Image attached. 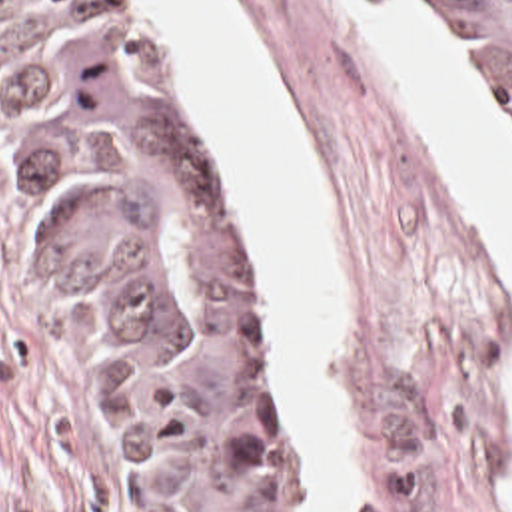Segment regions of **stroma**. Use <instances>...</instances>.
I'll list each match as a JSON object with an SVG mask.
<instances>
[{
	"instance_id": "obj_1",
	"label": "stroma",
	"mask_w": 512,
	"mask_h": 512,
	"mask_svg": "<svg viewBox=\"0 0 512 512\" xmlns=\"http://www.w3.org/2000/svg\"><path fill=\"white\" fill-rule=\"evenodd\" d=\"M115 1L215 163L259 293L277 440L307 512L315 478L291 420L253 221L157 15L143 0ZM399 1L434 27L512 157L504 113L444 13ZM219 3L263 71L343 255L351 342L327 372L353 422L349 468L367 478L363 512H512V279L486 211L341 1ZM0 512H155L87 305L47 251L11 165L1 101Z\"/></svg>"
}]
</instances>
